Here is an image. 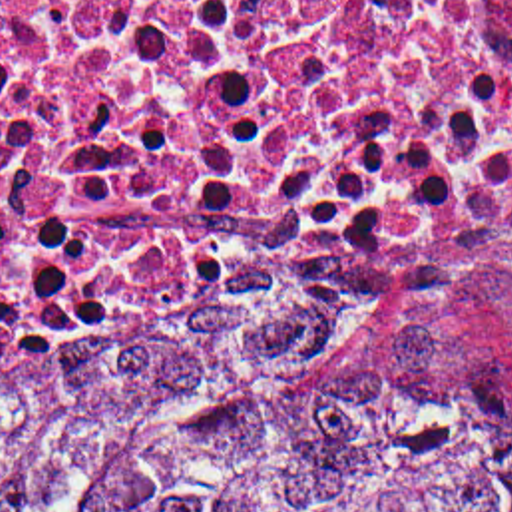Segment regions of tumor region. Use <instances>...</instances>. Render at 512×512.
Returning a JSON list of instances; mask_svg holds the SVG:
<instances>
[{"label":"tumor region","instance_id":"e687c5a6","mask_svg":"<svg viewBox=\"0 0 512 512\" xmlns=\"http://www.w3.org/2000/svg\"><path fill=\"white\" fill-rule=\"evenodd\" d=\"M0 512H512L424 342L119 320L0 360Z\"/></svg>","mask_w":512,"mask_h":512}]
</instances>
